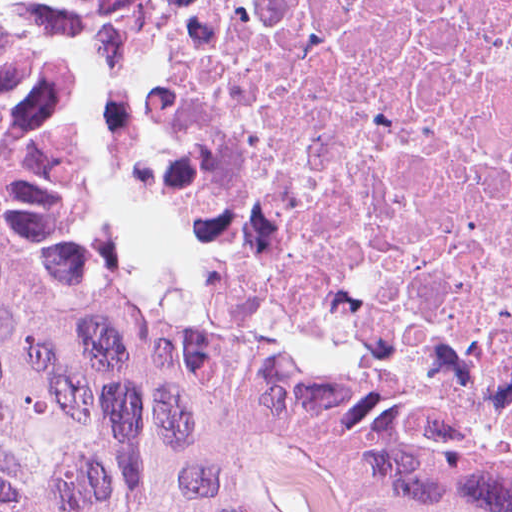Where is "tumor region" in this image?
I'll return each mask as SVG.
<instances>
[{
    "instance_id": "tumor-region-1",
    "label": "tumor region",
    "mask_w": 512,
    "mask_h": 512,
    "mask_svg": "<svg viewBox=\"0 0 512 512\" xmlns=\"http://www.w3.org/2000/svg\"><path fill=\"white\" fill-rule=\"evenodd\" d=\"M141 11L0 0V512H512V463L67 285L65 63Z\"/></svg>"
}]
</instances>
